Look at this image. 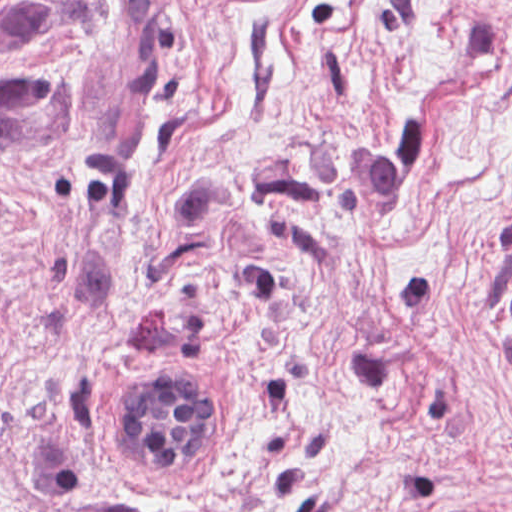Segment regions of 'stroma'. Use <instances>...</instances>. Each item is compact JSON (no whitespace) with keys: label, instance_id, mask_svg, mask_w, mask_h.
<instances>
[{"label":"stroma","instance_id":"obj_1","mask_svg":"<svg viewBox=\"0 0 512 512\" xmlns=\"http://www.w3.org/2000/svg\"><path fill=\"white\" fill-rule=\"evenodd\" d=\"M0 512H512V0H0Z\"/></svg>","mask_w":512,"mask_h":512}]
</instances>
